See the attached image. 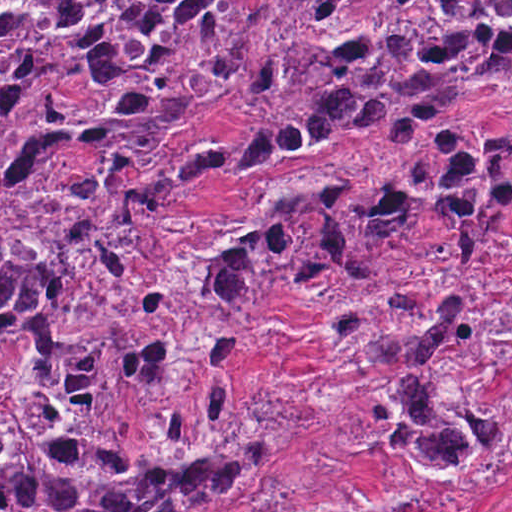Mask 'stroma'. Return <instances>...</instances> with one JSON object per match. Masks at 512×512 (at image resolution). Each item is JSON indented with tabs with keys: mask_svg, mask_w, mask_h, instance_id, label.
Listing matches in <instances>:
<instances>
[{
	"mask_svg": "<svg viewBox=\"0 0 512 512\" xmlns=\"http://www.w3.org/2000/svg\"><path fill=\"white\" fill-rule=\"evenodd\" d=\"M0 1H257V34L247 62L210 106L161 135L144 164L203 144H214L220 152L218 165L188 185L161 225L158 263L184 233L242 211L267 185L346 172H362L365 180L383 175L385 155L368 138L331 144L296 161L239 173L244 171L245 99L273 55L275 17L283 1L512 0ZM508 124H512V95L480 103L468 98L448 118V128L462 144ZM428 173L419 163L401 174ZM86 262L87 257L59 301L23 333L71 325ZM287 275L286 265L250 328V347L235 380L234 398L240 405L254 393L264 404H292L298 415L281 469L227 512H512V383L498 397L510 425L499 454L497 480L483 508H467L367 431L360 410L365 356L331 352L323 344L328 314L348 294V285L317 297H294L284 287ZM478 275L482 281L512 275V220L487 248Z\"/></svg>",
	"mask_w": 512,
	"mask_h": 512,
	"instance_id": "stroma-1",
	"label": "stroma"
}]
</instances>
